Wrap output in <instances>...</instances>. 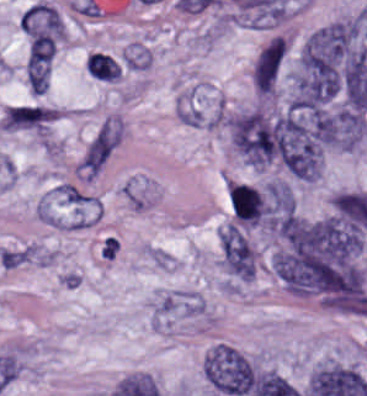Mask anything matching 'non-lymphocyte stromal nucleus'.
Wrapping results in <instances>:
<instances>
[{"mask_svg":"<svg viewBox=\"0 0 367 396\" xmlns=\"http://www.w3.org/2000/svg\"><path fill=\"white\" fill-rule=\"evenodd\" d=\"M201 367L211 387L227 396H247L257 375L253 360L227 344H214Z\"/></svg>","mask_w":367,"mask_h":396,"instance_id":"dd21d789","label":"non-lymphocyte stromal nucleus"},{"mask_svg":"<svg viewBox=\"0 0 367 396\" xmlns=\"http://www.w3.org/2000/svg\"><path fill=\"white\" fill-rule=\"evenodd\" d=\"M222 266L230 273L245 280H253L256 274L257 252L245 234L233 223L219 232Z\"/></svg>","mask_w":367,"mask_h":396,"instance_id":"a72fc3eb","label":"non-lymphocyte stromal nucleus"},{"mask_svg":"<svg viewBox=\"0 0 367 396\" xmlns=\"http://www.w3.org/2000/svg\"><path fill=\"white\" fill-rule=\"evenodd\" d=\"M58 116V107L37 103H18L5 110L0 122L3 128L47 133Z\"/></svg>","mask_w":367,"mask_h":396,"instance_id":"3746e769","label":"non-lymphocyte stromal nucleus"},{"mask_svg":"<svg viewBox=\"0 0 367 396\" xmlns=\"http://www.w3.org/2000/svg\"><path fill=\"white\" fill-rule=\"evenodd\" d=\"M205 311L198 295L189 290L176 289L164 294L156 303L153 316L156 322L167 323Z\"/></svg>","mask_w":367,"mask_h":396,"instance_id":"fc2b8d12","label":"non-lymphocyte stromal nucleus"},{"mask_svg":"<svg viewBox=\"0 0 367 396\" xmlns=\"http://www.w3.org/2000/svg\"><path fill=\"white\" fill-rule=\"evenodd\" d=\"M85 68L94 78L103 81H116L120 78L118 64L103 52H94L85 58Z\"/></svg>","mask_w":367,"mask_h":396,"instance_id":"81446118","label":"non-lymphocyte stromal nucleus"},{"mask_svg":"<svg viewBox=\"0 0 367 396\" xmlns=\"http://www.w3.org/2000/svg\"><path fill=\"white\" fill-rule=\"evenodd\" d=\"M121 63L125 69L144 70L151 64V49L138 43H131L124 50Z\"/></svg>","mask_w":367,"mask_h":396,"instance_id":"7c5642bf","label":"non-lymphocyte stromal nucleus"}]
</instances>
